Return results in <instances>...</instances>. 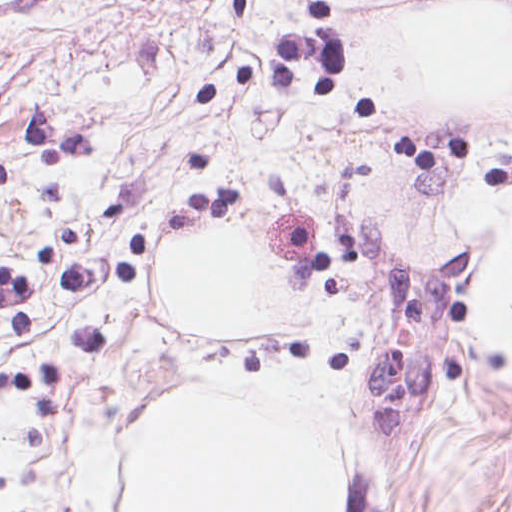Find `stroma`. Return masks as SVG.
<instances>
[{
  "label": "stroma",
  "mask_w": 512,
  "mask_h": 512,
  "mask_svg": "<svg viewBox=\"0 0 512 512\" xmlns=\"http://www.w3.org/2000/svg\"><path fill=\"white\" fill-rule=\"evenodd\" d=\"M473 1L0 0V265L37 327L0 322V512H76L75 429L129 385L312 361L303 335L178 325V235L228 218L293 291L376 301L431 132L352 82L357 42ZM222 187L236 210L189 194ZM366 331L324 368L354 371Z\"/></svg>",
  "instance_id": "obj_1"
}]
</instances>
